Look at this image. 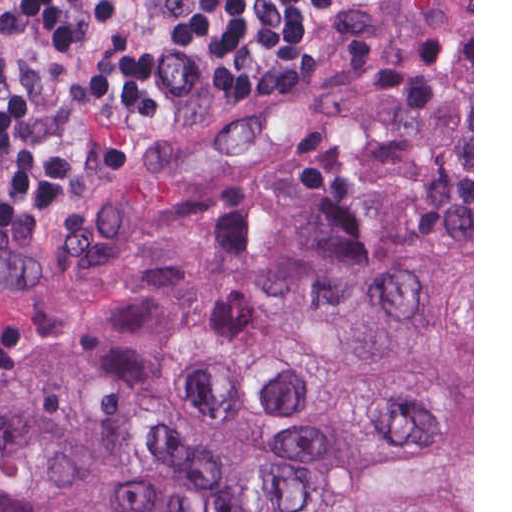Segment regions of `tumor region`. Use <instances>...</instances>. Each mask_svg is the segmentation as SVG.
Here are the masks:
<instances>
[{
    "instance_id": "tumor-region-1",
    "label": "tumor region",
    "mask_w": 512,
    "mask_h": 512,
    "mask_svg": "<svg viewBox=\"0 0 512 512\" xmlns=\"http://www.w3.org/2000/svg\"><path fill=\"white\" fill-rule=\"evenodd\" d=\"M0 512H472V73L1 380Z\"/></svg>"
}]
</instances>
